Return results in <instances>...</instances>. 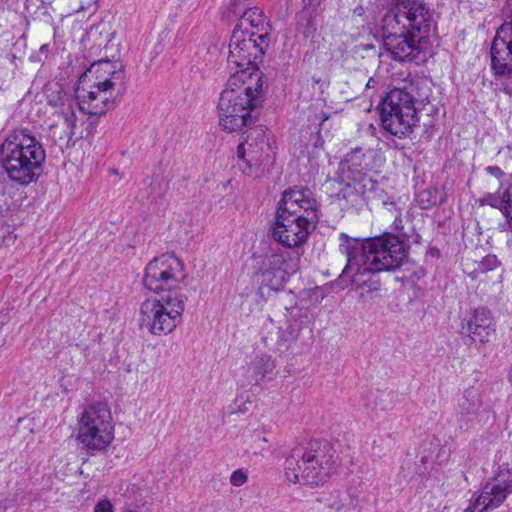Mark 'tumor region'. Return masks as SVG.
I'll list each match as a JSON object with an SVG mask.
<instances>
[{"instance_id":"tumor-region-1","label":"tumor region","mask_w":512,"mask_h":512,"mask_svg":"<svg viewBox=\"0 0 512 512\" xmlns=\"http://www.w3.org/2000/svg\"><path fill=\"white\" fill-rule=\"evenodd\" d=\"M110 1H0V203ZM302 129L238 266V329L301 319L339 282L446 294L512 340V1H310Z\"/></svg>"}]
</instances>
